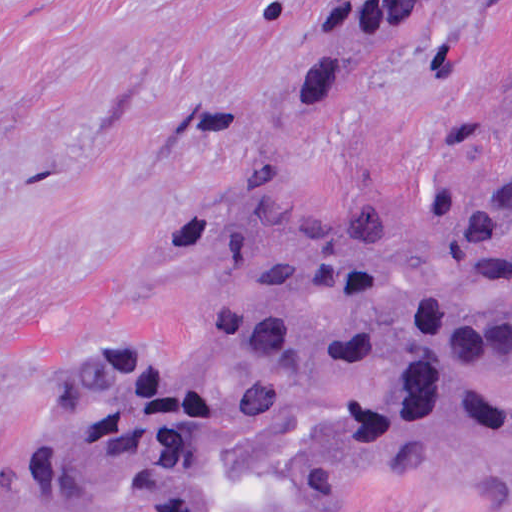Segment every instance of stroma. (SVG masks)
<instances>
[{"label":"stroma","instance_id":"1","mask_svg":"<svg viewBox=\"0 0 512 512\" xmlns=\"http://www.w3.org/2000/svg\"><path fill=\"white\" fill-rule=\"evenodd\" d=\"M421 6L372 80L293 111L289 63L364 8ZM511 86L512 0H0V512H57L18 492L34 406L70 361L192 356L204 323L167 254L197 216L235 195L337 216L480 182L512 137L474 119ZM330 512L499 510L399 469Z\"/></svg>","mask_w":512,"mask_h":512}]
</instances>
